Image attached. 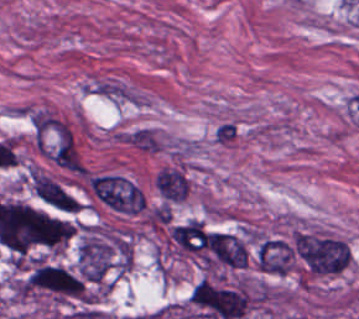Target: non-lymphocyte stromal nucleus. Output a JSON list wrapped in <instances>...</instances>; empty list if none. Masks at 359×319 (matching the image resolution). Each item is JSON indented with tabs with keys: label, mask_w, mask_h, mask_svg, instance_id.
<instances>
[{
	"label": "non-lymphocyte stromal nucleus",
	"mask_w": 359,
	"mask_h": 319,
	"mask_svg": "<svg viewBox=\"0 0 359 319\" xmlns=\"http://www.w3.org/2000/svg\"><path fill=\"white\" fill-rule=\"evenodd\" d=\"M119 140L131 148L148 154H160L169 149L164 134L148 125L126 129Z\"/></svg>",
	"instance_id": "obj_3"
},
{
	"label": "non-lymphocyte stromal nucleus",
	"mask_w": 359,
	"mask_h": 319,
	"mask_svg": "<svg viewBox=\"0 0 359 319\" xmlns=\"http://www.w3.org/2000/svg\"><path fill=\"white\" fill-rule=\"evenodd\" d=\"M190 192V179L175 166L165 168V201H182Z\"/></svg>",
	"instance_id": "obj_5"
},
{
	"label": "non-lymphocyte stromal nucleus",
	"mask_w": 359,
	"mask_h": 319,
	"mask_svg": "<svg viewBox=\"0 0 359 319\" xmlns=\"http://www.w3.org/2000/svg\"><path fill=\"white\" fill-rule=\"evenodd\" d=\"M90 186L111 210L135 215L144 208V196L139 187L122 176H96Z\"/></svg>",
	"instance_id": "obj_1"
},
{
	"label": "non-lymphocyte stromal nucleus",
	"mask_w": 359,
	"mask_h": 319,
	"mask_svg": "<svg viewBox=\"0 0 359 319\" xmlns=\"http://www.w3.org/2000/svg\"><path fill=\"white\" fill-rule=\"evenodd\" d=\"M82 93L131 105H143L148 100L142 92L111 77H97L85 82Z\"/></svg>",
	"instance_id": "obj_2"
},
{
	"label": "non-lymphocyte stromal nucleus",
	"mask_w": 359,
	"mask_h": 319,
	"mask_svg": "<svg viewBox=\"0 0 359 319\" xmlns=\"http://www.w3.org/2000/svg\"><path fill=\"white\" fill-rule=\"evenodd\" d=\"M170 238L184 252H198L207 247L206 234L202 222L190 220L175 226Z\"/></svg>",
	"instance_id": "obj_4"
}]
</instances>
